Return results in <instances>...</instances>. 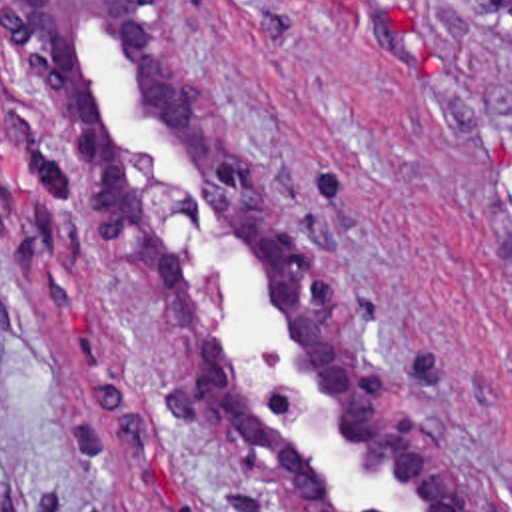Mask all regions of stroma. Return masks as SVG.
Instances as JSON below:
<instances>
[{
    "label": "stroma",
    "mask_w": 512,
    "mask_h": 512,
    "mask_svg": "<svg viewBox=\"0 0 512 512\" xmlns=\"http://www.w3.org/2000/svg\"><path fill=\"white\" fill-rule=\"evenodd\" d=\"M272 191L479 512H512V0H180ZM0 63V512H284L170 404Z\"/></svg>",
    "instance_id": "1"
}]
</instances>
